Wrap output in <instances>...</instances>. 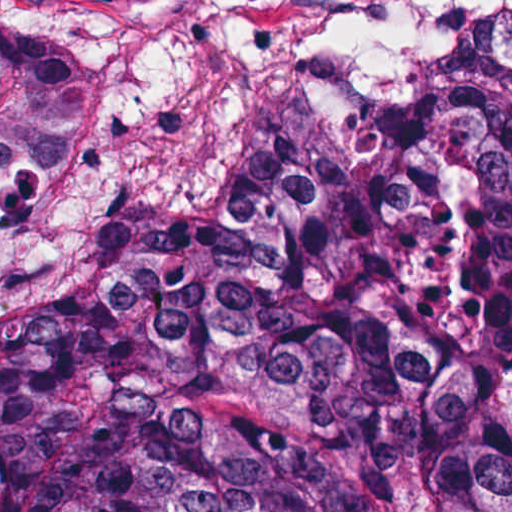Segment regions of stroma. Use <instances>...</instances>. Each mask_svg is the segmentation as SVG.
Listing matches in <instances>:
<instances>
[{
    "label": "stroma",
    "mask_w": 512,
    "mask_h": 512,
    "mask_svg": "<svg viewBox=\"0 0 512 512\" xmlns=\"http://www.w3.org/2000/svg\"><path fill=\"white\" fill-rule=\"evenodd\" d=\"M0 20L104 74V138L0 169V319L125 273L177 176L186 118L260 43L320 52L387 105L449 74H512V0H0Z\"/></svg>",
    "instance_id": "1"
}]
</instances>
